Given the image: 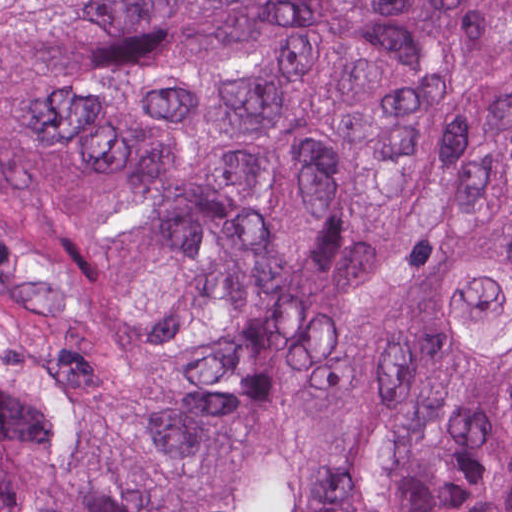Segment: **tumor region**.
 <instances>
[{
    "label": "tumor region",
    "instance_id": "tumor-region-1",
    "mask_svg": "<svg viewBox=\"0 0 512 512\" xmlns=\"http://www.w3.org/2000/svg\"><path fill=\"white\" fill-rule=\"evenodd\" d=\"M0 512H512V0H0Z\"/></svg>",
    "mask_w": 512,
    "mask_h": 512
}]
</instances>
